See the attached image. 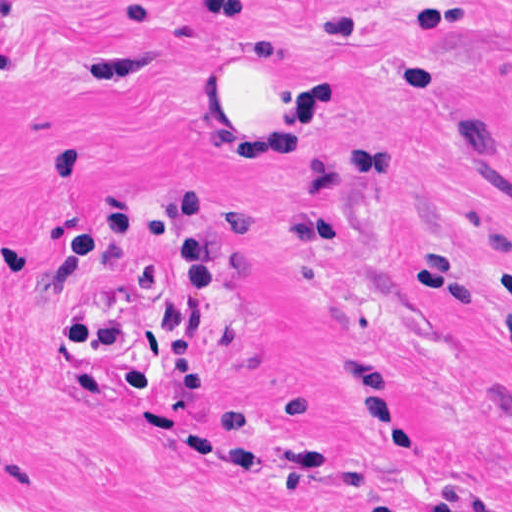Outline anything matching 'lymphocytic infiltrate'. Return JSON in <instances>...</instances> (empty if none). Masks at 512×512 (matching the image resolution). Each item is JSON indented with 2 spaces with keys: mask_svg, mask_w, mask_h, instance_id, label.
Returning a JSON list of instances; mask_svg holds the SVG:
<instances>
[{
  "mask_svg": "<svg viewBox=\"0 0 512 512\" xmlns=\"http://www.w3.org/2000/svg\"><path fill=\"white\" fill-rule=\"evenodd\" d=\"M14 26L12 14L0 0V49ZM211 209L210 197L199 189L173 193L148 213H139L125 192L109 191L94 217L70 231L54 255L53 266L60 273L88 260L105 240H144L163 230L172 234L174 290L158 315L164 339L121 368L120 381L130 395L149 394L167 382L178 395H200L207 386L206 367L195 349V323L215 294Z\"/></svg>",
  "mask_w": 512,
  "mask_h": 512,
  "instance_id": "lymphocytic-infiltrate-1",
  "label": "lymphocytic infiltrate"
}]
</instances>
